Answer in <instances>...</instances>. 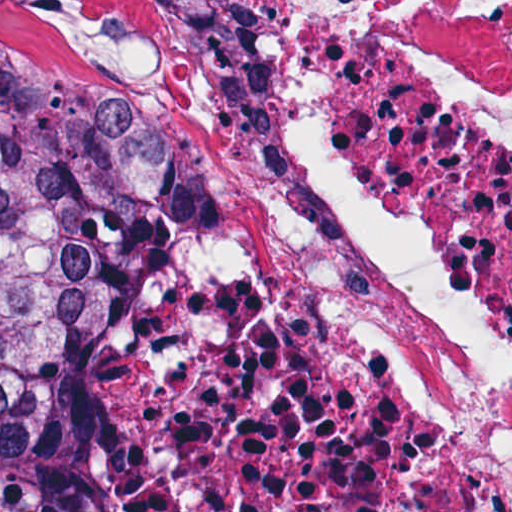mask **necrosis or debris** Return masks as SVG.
Masks as SVG:
<instances>
[{
    "mask_svg": "<svg viewBox=\"0 0 512 512\" xmlns=\"http://www.w3.org/2000/svg\"><path fill=\"white\" fill-rule=\"evenodd\" d=\"M165 80L66 511L512 512V1H174Z\"/></svg>",
    "mask_w": 512,
    "mask_h": 512,
    "instance_id": "4bbe7bcc",
    "label": "necrosis or debris"
}]
</instances>
